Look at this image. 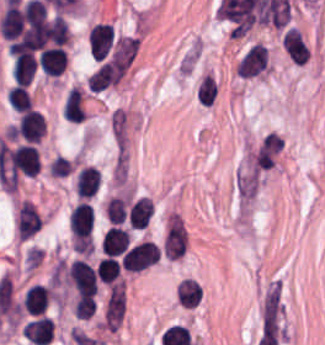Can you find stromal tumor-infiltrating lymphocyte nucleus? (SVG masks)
<instances>
[{
    "label": "stromal tumor-infiltrating lymphocyte nucleus",
    "mask_w": 325,
    "mask_h": 345,
    "mask_svg": "<svg viewBox=\"0 0 325 345\" xmlns=\"http://www.w3.org/2000/svg\"><path fill=\"white\" fill-rule=\"evenodd\" d=\"M198 300V282L191 277H184L177 285V302L193 307Z\"/></svg>",
    "instance_id": "e9af9c67"
},
{
    "label": "stromal tumor-infiltrating lymphocyte nucleus",
    "mask_w": 325,
    "mask_h": 345,
    "mask_svg": "<svg viewBox=\"0 0 325 345\" xmlns=\"http://www.w3.org/2000/svg\"><path fill=\"white\" fill-rule=\"evenodd\" d=\"M7 98L11 108L18 112L30 108L32 104L26 85L17 81L7 91Z\"/></svg>",
    "instance_id": "782c7336"
},
{
    "label": "stromal tumor-infiltrating lymphocyte nucleus",
    "mask_w": 325,
    "mask_h": 345,
    "mask_svg": "<svg viewBox=\"0 0 325 345\" xmlns=\"http://www.w3.org/2000/svg\"><path fill=\"white\" fill-rule=\"evenodd\" d=\"M281 45L285 53L293 60L304 63L309 58V48L295 27H288L281 36Z\"/></svg>",
    "instance_id": "2a367800"
},
{
    "label": "stromal tumor-infiltrating lymphocyte nucleus",
    "mask_w": 325,
    "mask_h": 345,
    "mask_svg": "<svg viewBox=\"0 0 325 345\" xmlns=\"http://www.w3.org/2000/svg\"><path fill=\"white\" fill-rule=\"evenodd\" d=\"M23 335L38 345H46L53 337V319L38 315L22 326Z\"/></svg>",
    "instance_id": "4803ca6d"
},
{
    "label": "stromal tumor-infiltrating lymphocyte nucleus",
    "mask_w": 325,
    "mask_h": 345,
    "mask_svg": "<svg viewBox=\"0 0 325 345\" xmlns=\"http://www.w3.org/2000/svg\"><path fill=\"white\" fill-rule=\"evenodd\" d=\"M42 223L33 203L22 199L15 216V230L20 237L27 238Z\"/></svg>",
    "instance_id": "4f13568d"
},
{
    "label": "stromal tumor-infiltrating lymphocyte nucleus",
    "mask_w": 325,
    "mask_h": 345,
    "mask_svg": "<svg viewBox=\"0 0 325 345\" xmlns=\"http://www.w3.org/2000/svg\"><path fill=\"white\" fill-rule=\"evenodd\" d=\"M283 137L276 130H269L250 149L245 168L251 172H262L271 167L281 147Z\"/></svg>",
    "instance_id": "bc302bb0"
},
{
    "label": "stromal tumor-infiltrating lymphocyte nucleus",
    "mask_w": 325,
    "mask_h": 345,
    "mask_svg": "<svg viewBox=\"0 0 325 345\" xmlns=\"http://www.w3.org/2000/svg\"><path fill=\"white\" fill-rule=\"evenodd\" d=\"M118 274V263L112 255H105L96 262V277L105 283H110Z\"/></svg>",
    "instance_id": "2e467ee5"
},
{
    "label": "stromal tumor-infiltrating lymphocyte nucleus",
    "mask_w": 325,
    "mask_h": 345,
    "mask_svg": "<svg viewBox=\"0 0 325 345\" xmlns=\"http://www.w3.org/2000/svg\"><path fill=\"white\" fill-rule=\"evenodd\" d=\"M48 291L40 282H33L24 291L21 305L28 313H42L48 298Z\"/></svg>",
    "instance_id": "3c572f05"
},
{
    "label": "stromal tumor-infiltrating lymphocyte nucleus",
    "mask_w": 325,
    "mask_h": 345,
    "mask_svg": "<svg viewBox=\"0 0 325 345\" xmlns=\"http://www.w3.org/2000/svg\"><path fill=\"white\" fill-rule=\"evenodd\" d=\"M129 242L127 229L112 225L103 232L101 237V252L105 255H118L127 249Z\"/></svg>",
    "instance_id": "2761f720"
},
{
    "label": "stromal tumor-infiltrating lymphocyte nucleus",
    "mask_w": 325,
    "mask_h": 345,
    "mask_svg": "<svg viewBox=\"0 0 325 345\" xmlns=\"http://www.w3.org/2000/svg\"><path fill=\"white\" fill-rule=\"evenodd\" d=\"M65 281L82 294H95L97 289L95 272L82 257H75L66 266Z\"/></svg>",
    "instance_id": "3290ff9b"
},
{
    "label": "stromal tumor-infiltrating lymphocyte nucleus",
    "mask_w": 325,
    "mask_h": 345,
    "mask_svg": "<svg viewBox=\"0 0 325 345\" xmlns=\"http://www.w3.org/2000/svg\"><path fill=\"white\" fill-rule=\"evenodd\" d=\"M152 211V203L148 196L134 199L127 209V223L134 228H144Z\"/></svg>",
    "instance_id": "04cf8593"
},
{
    "label": "stromal tumor-infiltrating lymphocyte nucleus",
    "mask_w": 325,
    "mask_h": 345,
    "mask_svg": "<svg viewBox=\"0 0 325 345\" xmlns=\"http://www.w3.org/2000/svg\"><path fill=\"white\" fill-rule=\"evenodd\" d=\"M96 305L92 294H78L73 304V314L81 319L91 318Z\"/></svg>",
    "instance_id": "7eef579d"
},
{
    "label": "stromal tumor-infiltrating lymphocyte nucleus",
    "mask_w": 325,
    "mask_h": 345,
    "mask_svg": "<svg viewBox=\"0 0 325 345\" xmlns=\"http://www.w3.org/2000/svg\"><path fill=\"white\" fill-rule=\"evenodd\" d=\"M266 65V49L255 42L248 46L235 64L237 74L240 77H252L263 71Z\"/></svg>",
    "instance_id": "9ea309e8"
},
{
    "label": "stromal tumor-infiltrating lymphocyte nucleus",
    "mask_w": 325,
    "mask_h": 345,
    "mask_svg": "<svg viewBox=\"0 0 325 345\" xmlns=\"http://www.w3.org/2000/svg\"><path fill=\"white\" fill-rule=\"evenodd\" d=\"M39 69L47 76H57L65 69L66 56L64 48L48 45L39 52Z\"/></svg>",
    "instance_id": "4245b91a"
},
{
    "label": "stromal tumor-infiltrating lymphocyte nucleus",
    "mask_w": 325,
    "mask_h": 345,
    "mask_svg": "<svg viewBox=\"0 0 325 345\" xmlns=\"http://www.w3.org/2000/svg\"><path fill=\"white\" fill-rule=\"evenodd\" d=\"M101 174L92 164H85L75 175L74 189L78 197H89L96 193Z\"/></svg>",
    "instance_id": "4c9ddf68"
},
{
    "label": "stromal tumor-infiltrating lymphocyte nucleus",
    "mask_w": 325,
    "mask_h": 345,
    "mask_svg": "<svg viewBox=\"0 0 325 345\" xmlns=\"http://www.w3.org/2000/svg\"><path fill=\"white\" fill-rule=\"evenodd\" d=\"M8 164L13 172L34 175L38 167V152L32 143H18L8 149Z\"/></svg>",
    "instance_id": "abfb95fc"
},
{
    "label": "stromal tumor-infiltrating lymphocyte nucleus",
    "mask_w": 325,
    "mask_h": 345,
    "mask_svg": "<svg viewBox=\"0 0 325 345\" xmlns=\"http://www.w3.org/2000/svg\"><path fill=\"white\" fill-rule=\"evenodd\" d=\"M85 115L86 111L81 90L77 86H70L64 99L63 117L70 122H81Z\"/></svg>",
    "instance_id": "42bb06b2"
},
{
    "label": "stromal tumor-infiltrating lymphocyte nucleus",
    "mask_w": 325,
    "mask_h": 345,
    "mask_svg": "<svg viewBox=\"0 0 325 345\" xmlns=\"http://www.w3.org/2000/svg\"><path fill=\"white\" fill-rule=\"evenodd\" d=\"M197 99L203 106H210L217 95V82L213 75L203 74L196 90Z\"/></svg>",
    "instance_id": "cac63f63"
},
{
    "label": "stromal tumor-infiltrating lymphocyte nucleus",
    "mask_w": 325,
    "mask_h": 345,
    "mask_svg": "<svg viewBox=\"0 0 325 345\" xmlns=\"http://www.w3.org/2000/svg\"><path fill=\"white\" fill-rule=\"evenodd\" d=\"M43 117L41 113L29 108L17 116L15 134L22 140L38 141L42 135Z\"/></svg>",
    "instance_id": "f3e2335f"
},
{
    "label": "stromal tumor-infiltrating lymphocyte nucleus",
    "mask_w": 325,
    "mask_h": 345,
    "mask_svg": "<svg viewBox=\"0 0 325 345\" xmlns=\"http://www.w3.org/2000/svg\"><path fill=\"white\" fill-rule=\"evenodd\" d=\"M160 257L159 248L150 239H143L127 248L121 254L123 269L139 271L152 265Z\"/></svg>",
    "instance_id": "52c7bb5b"
},
{
    "label": "stromal tumor-infiltrating lymphocyte nucleus",
    "mask_w": 325,
    "mask_h": 345,
    "mask_svg": "<svg viewBox=\"0 0 325 345\" xmlns=\"http://www.w3.org/2000/svg\"><path fill=\"white\" fill-rule=\"evenodd\" d=\"M36 67V61L31 52L27 50L18 53L11 65L12 77L16 81H19L27 85Z\"/></svg>",
    "instance_id": "9e4306bb"
}]
</instances>
